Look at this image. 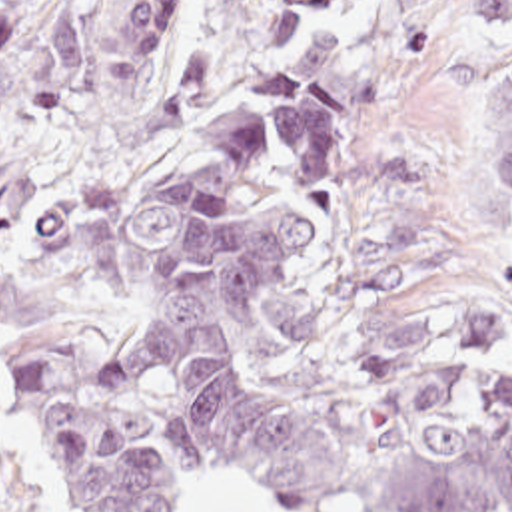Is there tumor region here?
<instances>
[{"instance_id": "e687c5a6", "label": "tumor region", "mask_w": 512, "mask_h": 512, "mask_svg": "<svg viewBox=\"0 0 512 512\" xmlns=\"http://www.w3.org/2000/svg\"><path fill=\"white\" fill-rule=\"evenodd\" d=\"M271 23L287 71L263 73L99 231L101 297L123 335L107 387L67 337L15 345L13 413L69 512H185L191 488L249 482L283 512H512V315L422 307L353 379L289 397L277 383L269 291L331 231L353 163L349 111L380 71L345 29L369 0H299ZM512 29V0H470ZM183 0H127L107 29L109 97L129 127H175L207 81V49L155 75ZM85 81L71 0H0V97L29 115ZM512 215V75L498 127ZM0 512H35L7 454Z\"/></svg>"}]
</instances>
